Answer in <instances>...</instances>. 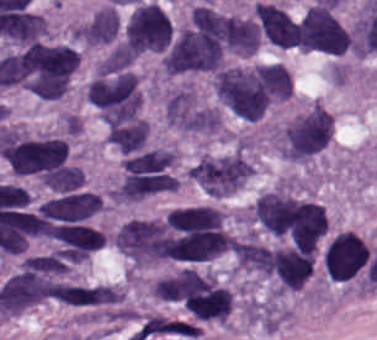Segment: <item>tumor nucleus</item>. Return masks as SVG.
I'll return each instance as SVG.
<instances>
[{"label": "tumor nucleus", "mask_w": 377, "mask_h": 340, "mask_svg": "<svg viewBox=\"0 0 377 340\" xmlns=\"http://www.w3.org/2000/svg\"><path fill=\"white\" fill-rule=\"evenodd\" d=\"M40 178L51 190L65 192L79 187L84 177L75 166H62L42 173Z\"/></svg>", "instance_id": "14"}, {"label": "tumor nucleus", "mask_w": 377, "mask_h": 340, "mask_svg": "<svg viewBox=\"0 0 377 340\" xmlns=\"http://www.w3.org/2000/svg\"><path fill=\"white\" fill-rule=\"evenodd\" d=\"M85 96L105 120L132 118L142 105L139 85L125 68H99L87 84Z\"/></svg>", "instance_id": "2"}, {"label": "tumor nucleus", "mask_w": 377, "mask_h": 340, "mask_svg": "<svg viewBox=\"0 0 377 340\" xmlns=\"http://www.w3.org/2000/svg\"><path fill=\"white\" fill-rule=\"evenodd\" d=\"M370 246L358 235L342 230L330 238L323 250V268L338 284H364Z\"/></svg>", "instance_id": "8"}, {"label": "tumor nucleus", "mask_w": 377, "mask_h": 340, "mask_svg": "<svg viewBox=\"0 0 377 340\" xmlns=\"http://www.w3.org/2000/svg\"><path fill=\"white\" fill-rule=\"evenodd\" d=\"M304 198L278 191L252 210L263 231L296 245Z\"/></svg>", "instance_id": "10"}, {"label": "tumor nucleus", "mask_w": 377, "mask_h": 340, "mask_svg": "<svg viewBox=\"0 0 377 340\" xmlns=\"http://www.w3.org/2000/svg\"><path fill=\"white\" fill-rule=\"evenodd\" d=\"M251 169L239 152H232L203 155L188 174L206 194L226 195L249 177Z\"/></svg>", "instance_id": "9"}, {"label": "tumor nucleus", "mask_w": 377, "mask_h": 340, "mask_svg": "<svg viewBox=\"0 0 377 340\" xmlns=\"http://www.w3.org/2000/svg\"><path fill=\"white\" fill-rule=\"evenodd\" d=\"M332 131V115L321 103H312L282 125L280 152L295 161L316 154Z\"/></svg>", "instance_id": "5"}, {"label": "tumor nucleus", "mask_w": 377, "mask_h": 340, "mask_svg": "<svg viewBox=\"0 0 377 340\" xmlns=\"http://www.w3.org/2000/svg\"><path fill=\"white\" fill-rule=\"evenodd\" d=\"M108 142L121 154L142 150L148 140V126L139 118L112 120L106 128Z\"/></svg>", "instance_id": "13"}, {"label": "tumor nucleus", "mask_w": 377, "mask_h": 340, "mask_svg": "<svg viewBox=\"0 0 377 340\" xmlns=\"http://www.w3.org/2000/svg\"><path fill=\"white\" fill-rule=\"evenodd\" d=\"M254 10L264 37L278 47H292L294 29L287 12L270 3H256Z\"/></svg>", "instance_id": "12"}, {"label": "tumor nucleus", "mask_w": 377, "mask_h": 340, "mask_svg": "<svg viewBox=\"0 0 377 340\" xmlns=\"http://www.w3.org/2000/svg\"><path fill=\"white\" fill-rule=\"evenodd\" d=\"M212 26L206 17L190 16L173 34L161 59L170 73L210 72Z\"/></svg>", "instance_id": "3"}, {"label": "tumor nucleus", "mask_w": 377, "mask_h": 340, "mask_svg": "<svg viewBox=\"0 0 377 340\" xmlns=\"http://www.w3.org/2000/svg\"><path fill=\"white\" fill-rule=\"evenodd\" d=\"M350 34L332 9L311 4L294 25L293 47L311 53L339 55L347 52Z\"/></svg>", "instance_id": "4"}, {"label": "tumor nucleus", "mask_w": 377, "mask_h": 340, "mask_svg": "<svg viewBox=\"0 0 377 340\" xmlns=\"http://www.w3.org/2000/svg\"><path fill=\"white\" fill-rule=\"evenodd\" d=\"M0 155L11 171L37 174L59 167L67 157V144L59 138L3 136Z\"/></svg>", "instance_id": "7"}, {"label": "tumor nucleus", "mask_w": 377, "mask_h": 340, "mask_svg": "<svg viewBox=\"0 0 377 340\" xmlns=\"http://www.w3.org/2000/svg\"><path fill=\"white\" fill-rule=\"evenodd\" d=\"M15 62L25 88L42 99L63 97L78 67L75 50L63 44H31Z\"/></svg>", "instance_id": "1"}, {"label": "tumor nucleus", "mask_w": 377, "mask_h": 340, "mask_svg": "<svg viewBox=\"0 0 377 340\" xmlns=\"http://www.w3.org/2000/svg\"><path fill=\"white\" fill-rule=\"evenodd\" d=\"M121 44L134 56L158 50L171 36L170 21L163 9L150 2L131 7L119 26Z\"/></svg>", "instance_id": "6"}, {"label": "tumor nucleus", "mask_w": 377, "mask_h": 340, "mask_svg": "<svg viewBox=\"0 0 377 340\" xmlns=\"http://www.w3.org/2000/svg\"><path fill=\"white\" fill-rule=\"evenodd\" d=\"M58 301L100 314L115 313L122 302L121 289L111 284L61 283Z\"/></svg>", "instance_id": "11"}]
</instances>
